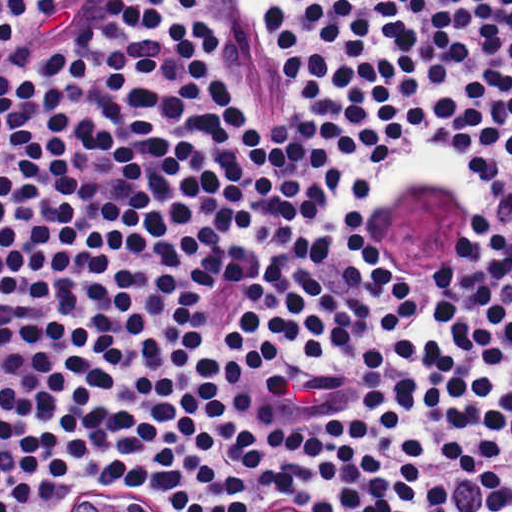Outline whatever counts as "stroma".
Here are the masks:
<instances>
[{
    "label": "stroma",
    "instance_id": "obj_1",
    "mask_svg": "<svg viewBox=\"0 0 512 512\" xmlns=\"http://www.w3.org/2000/svg\"><path fill=\"white\" fill-rule=\"evenodd\" d=\"M121 1L122 0H111L110 3L108 4V6L105 8V10L101 11L99 14H97L88 23V25L85 27V29L88 28L92 23H94L100 17L105 15L107 12L114 9L115 6L117 4H119ZM264 7H265V5H264ZM265 10L267 12L266 7H265ZM267 17L272 26L276 47H277L278 53L280 55V58H281V61L283 64V58H282V53H281V50H280V47L278 44L276 28H275L273 22L271 21L268 13H267ZM207 21H209V20H207ZM209 22L214 24L217 27V29L221 32V34L223 35L220 25H218L212 21H209ZM283 67H284V65H283ZM285 79H286V75H285ZM286 84L289 87L293 97L296 98L298 101H300L296 97V95L293 93L290 86L288 85L287 79H286ZM367 166L379 168L383 165H367ZM60 495L64 499H77L78 493H77L74 483L62 488ZM130 496L142 512H162V500H161L160 496H158L154 493H151V492H138V493H134ZM237 512H318V511L313 510V509L309 508L308 506H306L298 501H295L293 499L278 498V497H274V496H265V497L253 499V500L245 503L243 506H241L238 509Z\"/></svg>",
    "mask_w": 512,
    "mask_h": 512
}]
</instances>
